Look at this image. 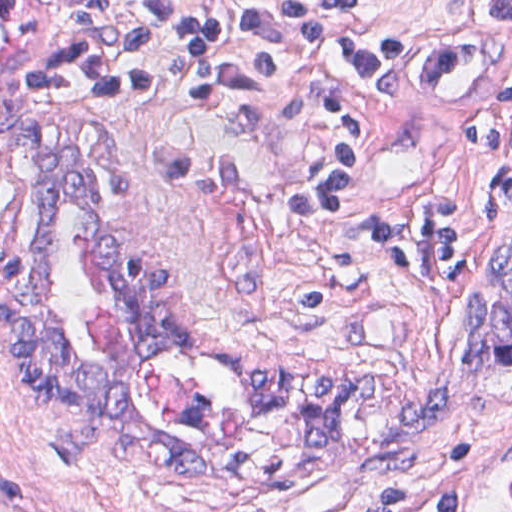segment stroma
Listing matches in <instances>:
<instances>
[{"instance_id": "stroma-1", "label": "stroma", "mask_w": 512, "mask_h": 512, "mask_svg": "<svg viewBox=\"0 0 512 512\" xmlns=\"http://www.w3.org/2000/svg\"><path fill=\"white\" fill-rule=\"evenodd\" d=\"M361 11L401 32V65L382 84L338 83L376 132L379 163L348 208L296 215L289 186L339 139L337 106L301 52L275 43L279 83L266 95L184 100L157 48L149 93L65 104L28 91L62 54L57 1L0 0V512L1 466L62 512H367L380 487L441 485H454L459 512H512V219L493 213L495 153L468 138L487 95L512 82V23L490 16V0ZM19 118L94 156L110 232L168 272L176 316L217 354L308 382L377 379L344 435L307 460L306 414L247 400L203 349L130 338L94 220L67 199L48 209L65 343L162 440L215 469L179 478L107 446L53 455L62 408L20 380L1 329V138ZM433 191L458 197L471 223L461 281L378 252V215Z\"/></svg>"}]
</instances>
